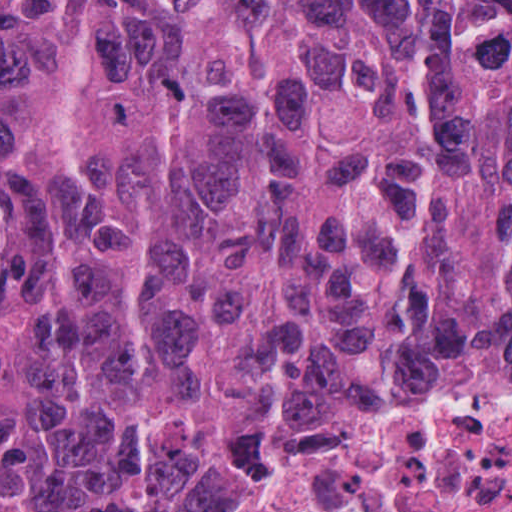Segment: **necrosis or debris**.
I'll return each mask as SVG.
<instances>
[{
	"label": "necrosis or debris",
	"instance_id": "necrosis-or-debris-1",
	"mask_svg": "<svg viewBox=\"0 0 512 512\" xmlns=\"http://www.w3.org/2000/svg\"><path fill=\"white\" fill-rule=\"evenodd\" d=\"M285 512H512V372L396 382L332 434Z\"/></svg>",
	"mask_w": 512,
	"mask_h": 512
}]
</instances>
